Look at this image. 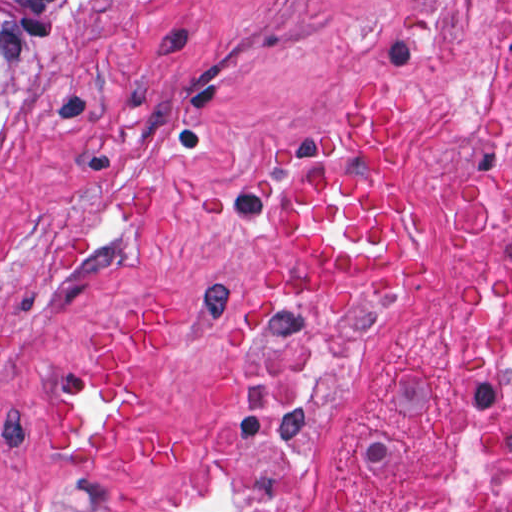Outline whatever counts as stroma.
Returning a JSON list of instances; mask_svg holds the SVG:
<instances>
[{
	"mask_svg": "<svg viewBox=\"0 0 512 512\" xmlns=\"http://www.w3.org/2000/svg\"><path fill=\"white\" fill-rule=\"evenodd\" d=\"M75 1L0 114V512H187L231 438L227 360L268 304L358 318L352 370L274 512H356L446 466L443 289L461 188L512 75V0ZM408 96L394 149L432 201L408 292L328 291L282 228L286 143L339 132L342 92ZM190 467L80 448L53 401L135 301Z\"/></svg>",
	"mask_w": 512,
	"mask_h": 512,
	"instance_id": "obj_1",
	"label": "stroma"
}]
</instances>
